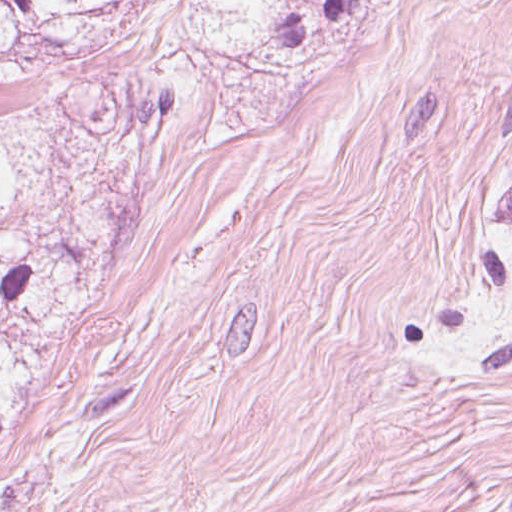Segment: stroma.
<instances>
[{"mask_svg": "<svg viewBox=\"0 0 512 512\" xmlns=\"http://www.w3.org/2000/svg\"><path fill=\"white\" fill-rule=\"evenodd\" d=\"M512 0H488L322 512H512Z\"/></svg>", "mask_w": 512, "mask_h": 512, "instance_id": "stroma-1", "label": "stroma"}]
</instances>
